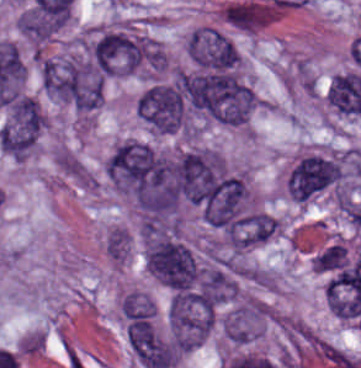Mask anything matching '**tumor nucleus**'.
Masks as SVG:
<instances>
[{"label":"tumor nucleus","mask_w":361,"mask_h":368,"mask_svg":"<svg viewBox=\"0 0 361 368\" xmlns=\"http://www.w3.org/2000/svg\"><path fill=\"white\" fill-rule=\"evenodd\" d=\"M342 153L313 150L300 156L286 179L291 199L306 202L345 178Z\"/></svg>","instance_id":"2f306a5c"},{"label":"tumor nucleus","mask_w":361,"mask_h":368,"mask_svg":"<svg viewBox=\"0 0 361 368\" xmlns=\"http://www.w3.org/2000/svg\"><path fill=\"white\" fill-rule=\"evenodd\" d=\"M145 262L155 279L167 288L188 290L198 281L199 268L194 254L182 243L150 240Z\"/></svg>","instance_id":"8643909e"},{"label":"tumor nucleus","mask_w":361,"mask_h":368,"mask_svg":"<svg viewBox=\"0 0 361 368\" xmlns=\"http://www.w3.org/2000/svg\"><path fill=\"white\" fill-rule=\"evenodd\" d=\"M185 51L202 70L235 71L239 52L226 33L214 25L201 24L187 37Z\"/></svg>","instance_id":"5ab6c2c4"},{"label":"tumor nucleus","mask_w":361,"mask_h":368,"mask_svg":"<svg viewBox=\"0 0 361 368\" xmlns=\"http://www.w3.org/2000/svg\"><path fill=\"white\" fill-rule=\"evenodd\" d=\"M47 118L34 96L20 95L1 129L6 152H26L37 141Z\"/></svg>","instance_id":"2cbd58db"},{"label":"tumor nucleus","mask_w":361,"mask_h":368,"mask_svg":"<svg viewBox=\"0 0 361 368\" xmlns=\"http://www.w3.org/2000/svg\"><path fill=\"white\" fill-rule=\"evenodd\" d=\"M266 319L264 302L246 299L224 315L222 330L231 344H246L262 333Z\"/></svg>","instance_id":"3d1891a8"},{"label":"tumor nucleus","mask_w":361,"mask_h":368,"mask_svg":"<svg viewBox=\"0 0 361 368\" xmlns=\"http://www.w3.org/2000/svg\"><path fill=\"white\" fill-rule=\"evenodd\" d=\"M151 298L136 290L125 291L120 302V315L125 322H151L155 318Z\"/></svg>","instance_id":"2083b535"},{"label":"tumor nucleus","mask_w":361,"mask_h":368,"mask_svg":"<svg viewBox=\"0 0 361 368\" xmlns=\"http://www.w3.org/2000/svg\"><path fill=\"white\" fill-rule=\"evenodd\" d=\"M131 246V236L125 227L113 226L107 233L104 249L108 258L115 264L124 266Z\"/></svg>","instance_id":"8087334f"},{"label":"tumor nucleus","mask_w":361,"mask_h":368,"mask_svg":"<svg viewBox=\"0 0 361 368\" xmlns=\"http://www.w3.org/2000/svg\"><path fill=\"white\" fill-rule=\"evenodd\" d=\"M347 263V250L341 243H334L312 258L314 273L343 268Z\"/></svg>","instance_id":"c2bd9aea"}]
</instances>
